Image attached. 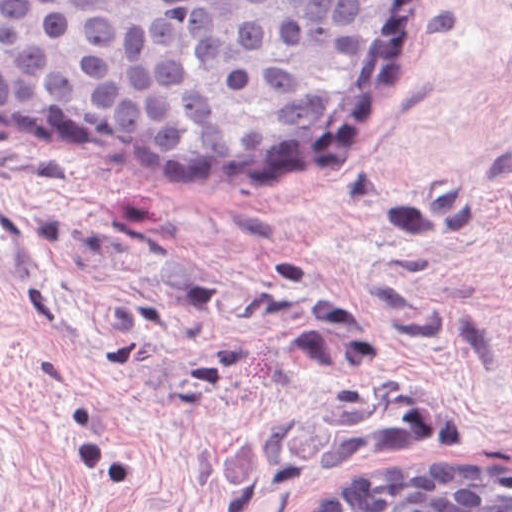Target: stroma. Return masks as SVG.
<instances>
[{"instance_id": "stroma-1", "label": "stroma", "mask_w": 512, "mask_h": 512, "mask_svg": "<svg viewBox=\"0 0 512 512\" xmlns=\"http://www.w3.org/2000/svg\"><path fill=\"white\" fill-rule=\"evenodd\" d=\"M47 270L0 283V512H297L512 462V12L431 0L370 147L292 196L0 132Z\"/></svg>"}]
</instances>
